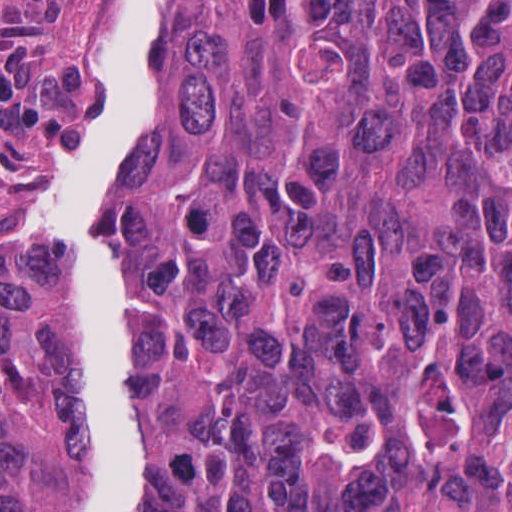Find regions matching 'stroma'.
Segmentation results:
<instances>
[{
  "label": "stroma",
  "instance_id": "obj_1",
  "mask_svg": "<svg viewBox=\"0 0 512 512\" xmlns=\"http://www.w3.org/2000/svg\"><path fill=\"white\" fill-rule=\"evenodd\" d=\"M94 1L125 9L88 102L87 119L148 25V1L512 0H0V279L27 245L63 152L69 119L98 57ZM140 78L127 122L140 88ZM45 266L43 228L20 257ZM60 472L53 367L23 425L0 512H51Z\"/></svg>",
  "mask_w": 512,
  "mask_h": 512
}]
</instances>
